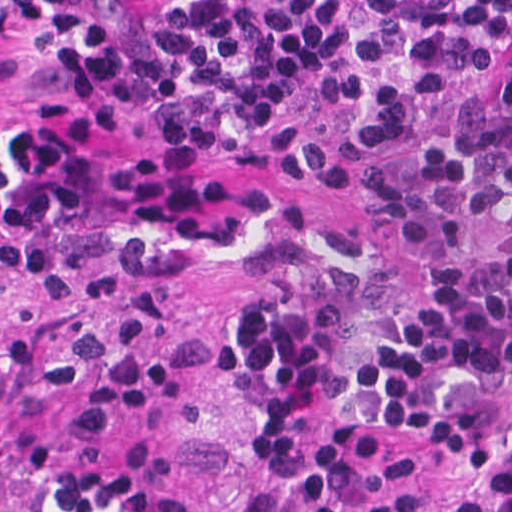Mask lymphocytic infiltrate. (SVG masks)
I'll list each match as a JSON object with an SVG mask.
<instances>
[{
  "label": "lymphocytic infiltrate",
  "mask_w": 512,
  "mask_h": 512,
  "mask_svg": "<svg viewBox=\"0 0 512 512\" xmlns=\"http://www.w3.org/2000/svg\"><path fill=\"white\" fill-rule=\"evenodd\" d=\"M42 103L0 104V288L94 245H224L232 331L294 512H505L512 453L440 497L431 450L512 430V0H0ZM171 299L0 317V512H202L116 434L207 379Z\"/></svg>",
  "instance_id": "lymphocytic-infiltrate-1"
}]
</instances>
